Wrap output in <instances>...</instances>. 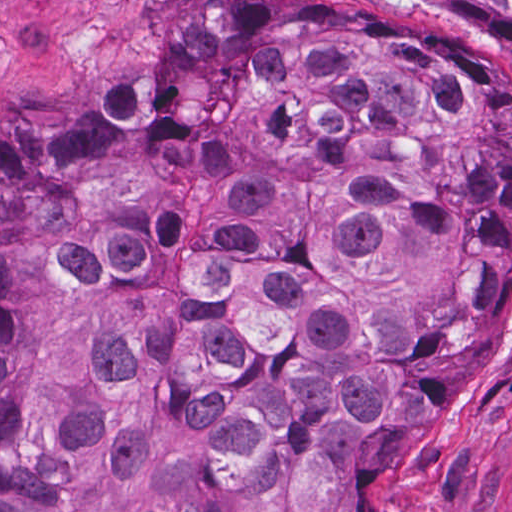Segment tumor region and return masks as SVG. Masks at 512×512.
I'll use <instances>...</instances> for the list:
<instances>
[{"mask_svg":"<svg viewBox=\"0 0 512 512\" xmlns=\"http://www.w3.org/2000/svg\"><path fill=\"white\" fill-rule=\"evenodd\" d=\"M393 1L485 44L226 0L0 111V512L379 511L512 254V0Z\"/></svg>","mask_w":512,"mask_h":512,"instance_id":"tumor-region-1","label":"tumor region"}]
</instances>
